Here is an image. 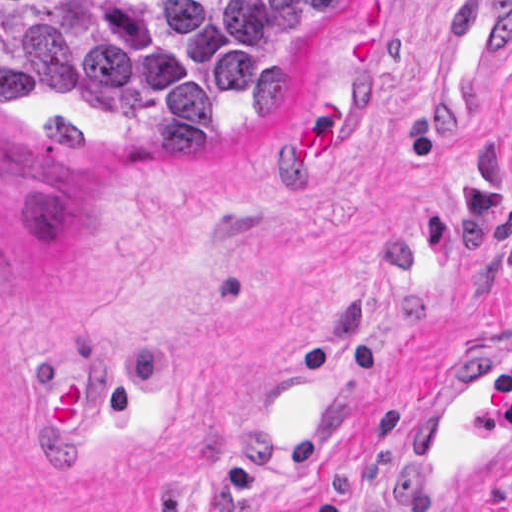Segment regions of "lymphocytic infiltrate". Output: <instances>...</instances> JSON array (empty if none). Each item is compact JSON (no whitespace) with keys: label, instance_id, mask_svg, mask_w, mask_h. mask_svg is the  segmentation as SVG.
<instances>
[{"label":"lymphocytic infiltrate","instance_id":"lymphocytic-infiltrate-1","mask_svg":"<svg viewBox=\"0 0 512 512\" xmlns=\"http://www.w3.org/2000/svg\"><path fill=\"white\" fill-rule=\"evenodd\" d=\"M271 512H298L294 508H280ZM317 512H365L362 503L342 497H332L324 501ZM478 512H485L479 510Z\"/></svg>","mask_w":512,"mask_h":512}]
</instances>
